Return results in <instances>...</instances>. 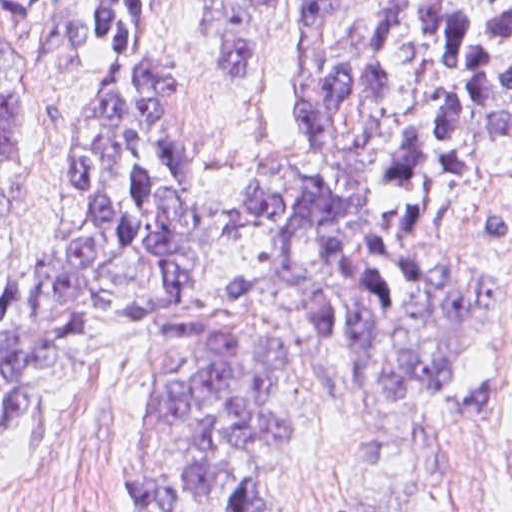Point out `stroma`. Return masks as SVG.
Masks as SVG:
<instances>
[{
  "label": "stroma",
  "instance_id": "obj_1",
  "mask_svg": "<svg viewBox=\"0 0 512 512\" xmlns=\"http://www.w3.org/2000/svg\"><path fill=\"white\" fill-rule=\"evenodd\" d=\"M151 1L137 44L110 59L67 58L34 41L32 192L19 210L15 257L31 266L48 245L88 121L110 88L142 70L189 72L184 125L195 158L201 240L195 281L208 297L248 287L234 318L278 336L292 358V388L312 427L294 451L280 501L266 512H351L367 467L357 421L322 424L319 360L269 268L235 242L237 201L270 167L302 150L288 75L290 40L304 1L512 0H0ZM223 1H267L243 76L223 77L207 53ZM512 210V167L478 154L467 196L435 216L427 245L463 262L501 295L470 328L450 392L405 427L423 482L395 460L377 463L362 512H512V264L483 227V213ZM186 378L158 351L135 350L42 392L12 430L0 458V512H128L132 432L153 410L179 401Z\"/></svg>",
  "mask_w": 512,
  "mask_h": 512
}]
</instances>
